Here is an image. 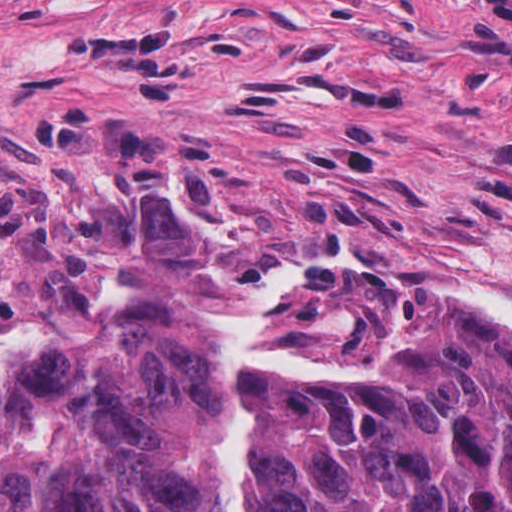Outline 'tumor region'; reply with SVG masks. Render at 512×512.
<instances>
[{
  "label": "tumor region",
  "mask_w": 512,
  "mask_h": 512,
  "mask_svg": "<svg viewBox=\"0 0 512 512\" xmlns=\"http://www.w3.org/2000/svg\"><path fill=\"white\" fill-rule=\"evenodd\" d=\"M290 311L275 347L349 370L246 382L243 512H512V336L383 276H327ZM229 324L139 297L80 314L0 397V512H202Z\"/></svg>",
  "instance_id": "1"
}]
</instances>
